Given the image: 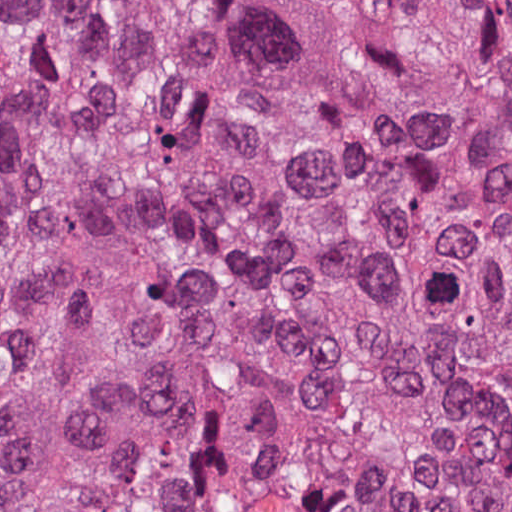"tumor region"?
Masks as SVG:
<instances>
[{
    "mask_svg": "<svg viewBox=\"0 0 512 512\" xmlns=\"http://www.w3.org/2000/svg\"><path fill=\"white\" fill-rule=\"evenodd\" d=\"M0 512H512V0H0Z\"/></svg>",
    "mask_w": 512,
    "mask_h": 512,
    "instance_id": "tumor-region-1",
    "label": "tumor region"
}]
</instances>
